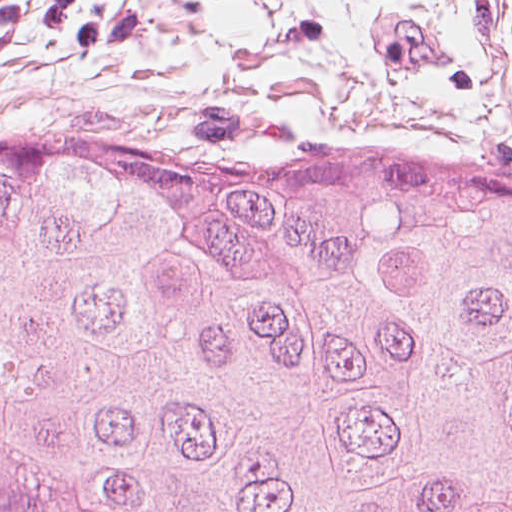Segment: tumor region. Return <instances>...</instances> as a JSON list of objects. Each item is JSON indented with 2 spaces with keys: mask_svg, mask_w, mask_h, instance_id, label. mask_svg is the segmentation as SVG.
Segmentation results:
<instances>
[{
  "mask_svg": "<svg viewBox=\"0 0 512 512\" xmlns=\"http://www.w3.org/2000/svg\"><path fill=\"white\" fill-rule=\"evenodd\" d=\"M0 512H512V170L0 120Z\"/></svg>",
  "mask_w": 512,
  "mask_h": 512,
  "instance_id": "obj_1",
  "label": "tumor region"
}]
</instances>
